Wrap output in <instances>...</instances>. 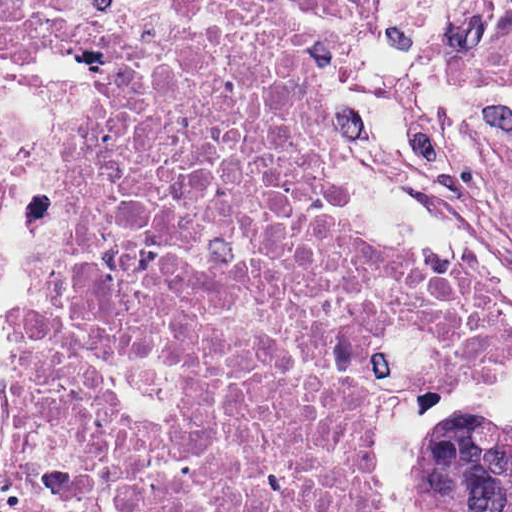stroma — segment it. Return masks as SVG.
I'll list each match as a JSON object with an SVG mask.
<instances>
[{"label":"stroma","mask_w":512,"mask_h":512,"mask_svg":"<svg viewBox=\"0 0 512 512\" xmlns=\"http://www.w3.org/2000/svg\"><path fill=\"white\" fill-rule=\"evenodd\" d=\"M88 9L317 20L334 66L347 222L372 245L452 260L512 308V0H0V15L71 20ZM27 56L68 97V129L4 268L0 366L5 296L44 300L40 280L64 228L71 166L96 110V85ZM459 413L512 420V353L421 396H373L377 512H423L416 461L440 421ZM0 512H8L1 476Z\"/></svg>","instance_id":"stroma-1"}]
</instances>
